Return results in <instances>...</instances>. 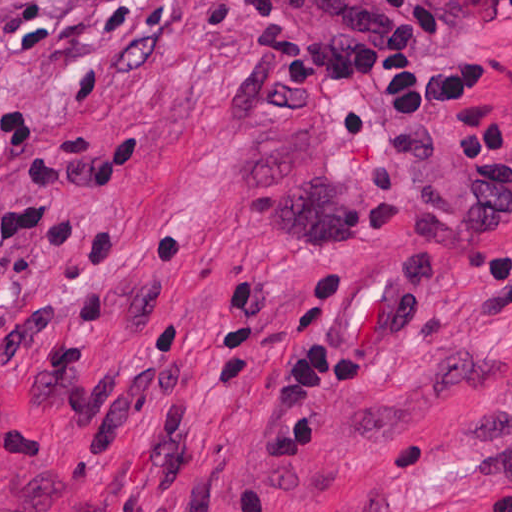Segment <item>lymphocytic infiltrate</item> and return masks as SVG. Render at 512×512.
<instances>
[{
	"instance_id": "1",
	"label": "lymphocytic infiltrate",
	"mask_w": 512,
	"mask_h": 512,
	"mask_svg": "<svg viewBox=\"0 0 512 512\" xmlns=\"http://www.w3.org/2000/svg\"><path fill=\"white\" fill-rule=\"evenodd\" d=\"M240 1L265 43L290 52L283 82L333 91L353 138L370 133V114L343 104L342 93L382 88L385 143L402 166L430 158V138L421 127L427 119L481 185L512 181V162L501 155L505 127L498 112L466 106L486 76L483 63L471 60L446 74L421 65V57L450 29L451 13L442 0ZM345 291V270L336 263L306 276L286 304L285 345L292 357L265 412L276 462H299L331 397L360 383L359 356L332 349Z\"/></svg>"
}]
</instances>
